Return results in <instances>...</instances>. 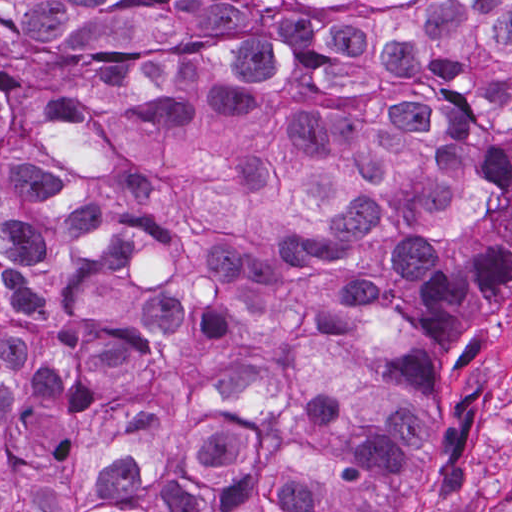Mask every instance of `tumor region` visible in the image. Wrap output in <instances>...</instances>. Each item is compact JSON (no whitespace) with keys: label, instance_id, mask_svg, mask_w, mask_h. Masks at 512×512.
<instances>
[{"label":"tumor region","instance_id":"1","mask_svg":"<svg viewBox=\"0 0 512 512\" xmlns=\"http://www.w3.org/2000/svg\"><path fill=\"white\" fill-rule=\"evenodd\" d=\"M511 292L512 0H1V512H465Z\"/></svg>","mask_w":512,"mask_h":512}]
</instances>
